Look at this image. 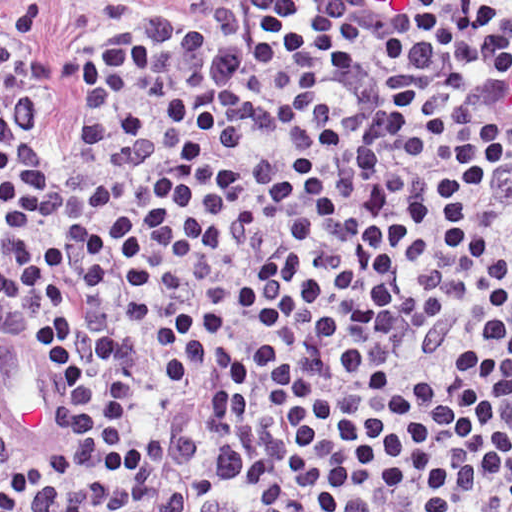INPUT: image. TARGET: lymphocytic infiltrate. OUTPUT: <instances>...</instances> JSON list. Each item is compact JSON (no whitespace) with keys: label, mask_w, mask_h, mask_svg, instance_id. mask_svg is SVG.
Instances as JSON below:
<instances>
[{"label":"lymphocytic infiltrate","mask_w":512,"mask_h":512,"mask_svg":"<svg viewBox=\"0 0 512 512\" xmlns=\"http://www.w3.org/2000/svg\"><path fill=\"white\" fill-rule=\"evenodd\" d=\"M81 63L61 164L1 51V512H512V1Z\"/></svg>","instance_id":"f902f5d3"}]
</instances>
